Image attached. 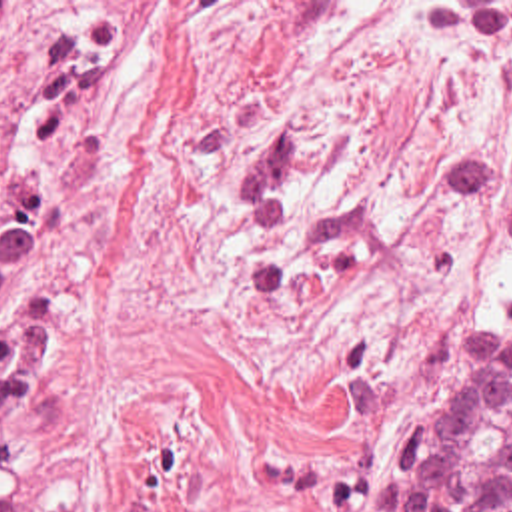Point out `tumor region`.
<instances>
[{
    "label": "tumor region",
    "instance_id": "obj_1",
    "mask_svg": "<svg viewBox=\"0 0 512 512\" xmlns=\"http://www.w3.org/2000/svg\"><path fill=\"white\" fill-rule=\"evenodd\" d=\"M47 374L39 326L0 334V512H83V494L19 472L12 432ZM373 512H512V304L481 330L439 406L379 476Z\"/></svg>",
    "mask_w": 512,
    "mask_h": 512
}]
</instances>
